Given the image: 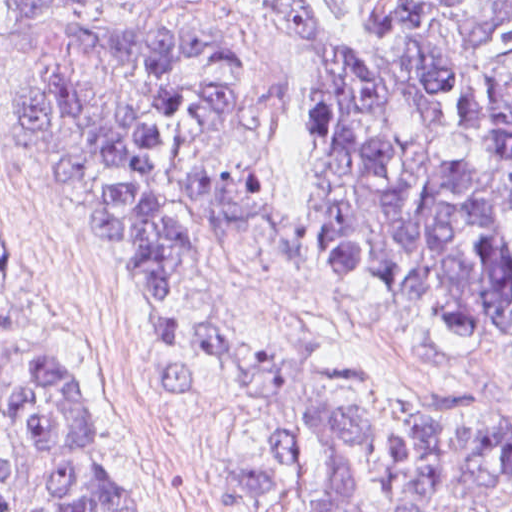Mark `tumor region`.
<instances>
[{
	"label": "tumor region",
	"instance_id": "obj_1",
	"mask_svg": "<svg viewBox=\"0 0 512 512\" xmlns=\"http://www.w3.org/2000/svg\"><path fill=\"white\" fill-rule=\"evenodd\" d=\"M126 0H10L49 189L153 297L171 337L195 259L267 193L256 63L137 22ZM320 53V243L334 296L512 389V0H299ZM20 249L0 232V274ZM216 424L253 512H512V426L446 412L345 358L210 320L160 359ZM0 512H137L102 466L85 374L0 384Z\"/></svg>",
	"mask_w": 512,
	"mask_h": 512
}]
</instances>
